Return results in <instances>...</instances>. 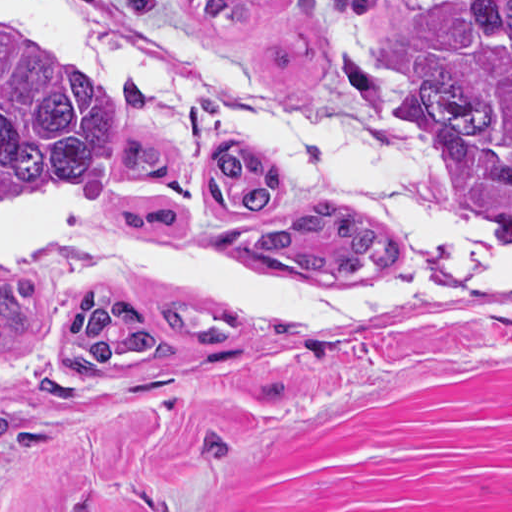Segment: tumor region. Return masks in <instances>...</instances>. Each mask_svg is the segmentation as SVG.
Wrapping results in <instances>:
<instances>
[{
	"instance_id": "tumor-region-1",
	"label": "tumor region",
	"mask_w": 512,
	"mask_h": 512,
	"mask_svg": "<svg viewBox=\"0 0 512 512\" xmlns=\"http://www.w3.org/2000/svg\"><path fill=\"white\" fill-rule=\"evenodd\" d=\"M259 1L193 4L206 24L232 28ZM322 1L333 12H361L375 0ZM130 9L151 18L159 0H130ZM372 67L341 61L371 111L382 114L387 81ZM404 97L440 156L512 211V0H438L410 53ZM60 194L98 201L132 236L197 261L345 284L401 283L415 266V249L400 232L288 201L277 168L250 143H213L201 191L189 196L161 130L129 128L114 92L95 75L0 30V229ZM165 309L184 343L228 344L241 329L220 315L201 324L188 309ZM36 312L34 280L0 278V340L30 337ZM168 354L130 302L90 293L71 314L64 358L75 378ZM23 431L8 421L0 396V452Z\"/></svg>"
}]
</instances>
